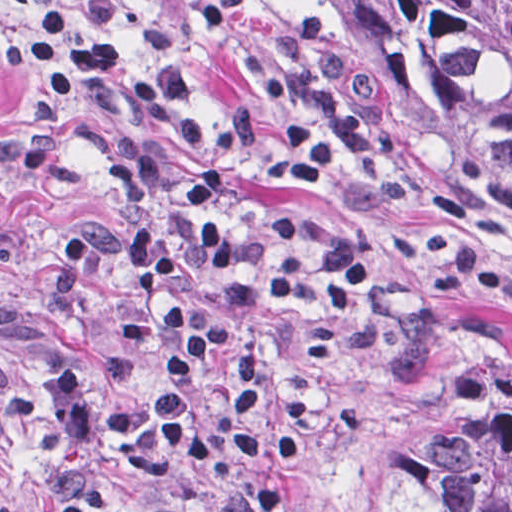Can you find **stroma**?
I'll return each mask as SVG.
<instances>
[{"mask_svg":"<svg viewBox=\"0 0 512 512\" xmlns=\"http://www.w3.org/2000/svg\"><path fill=\"white\" fill-rule=\"evenodd\" d=\"M126 9L130 51L170 60L198 83L209 127L245 102L261 113V59L275 29L309 8L293 0H115ZM79 0H0V99L10 92L3 43L43 3L65 12ZM343 87L367 116L365 142L330 176L293 188L259 181L255 212L302 210L378 237L384 298L397 317L384 351L342 348L331 361L291 351V385L327 387L372 406L358 432L328 421L317 453L286 473L301 499L289 512H405L408 443L448 397L489 376H512V228L411 145L363 88L345 54ZM29 126L0 112V512H61L79 483L110 472L73 447L42 380L80 373L100 406L114 407L162 374L158 294L143 298L148 345L124 349L120 318L129 287L120 204L105 173L57 188L25 161ZM117 512H277L237 464L184 483L138 490Z\"/></svg>","mask_w":512,"mask_h":512,"instance_id":"stroma-1","label":"stroma"}]
</instances>
